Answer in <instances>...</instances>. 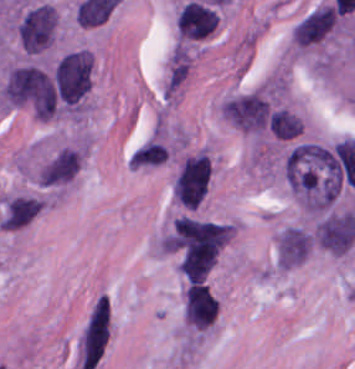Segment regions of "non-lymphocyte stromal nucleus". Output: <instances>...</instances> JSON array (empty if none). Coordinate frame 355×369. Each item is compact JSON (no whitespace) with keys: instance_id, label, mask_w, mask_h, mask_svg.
I'll list each match as a JSON object with an SVG mask.
<instances>
[{"instance_id":"non-lymphocyte-stromal-nucleus-1","label":"non-lymphocyte stromal nucleus","mask_w":355,"mask_h":369,"mask_svg":"<svg viewBox=\"0 0 355 369\" xmlns=\"http://www.w3.org/2000/svg\"><path fill=\"white\" fill-rule=\"evenodd\" d=\"M355 239V215L350 211L332 212L318 222L315 241L334 254H343Z\"/></svg>"},{"instance_id":"non-lymphocyte-stromal-nucleus-2","label":"non-lymphocyte stromal nucleus","mask_w":355,"mask_h":369,"mask_svg":"<svg viewBox=\"0 0 355 369\" xmlns=\"http://www.w3.org/2000/svg\"><path fill=\"white\" fill-rule=\"evenodd\" d=\"M311 252L309 229L290 225L275 240V262L280 267H295Z\"/></svg>"}]
</instances>
